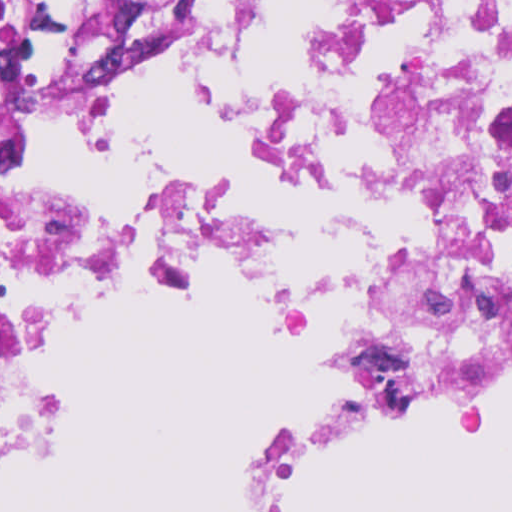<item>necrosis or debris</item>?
<instances>
[{"instance_id": "necrosis-or-debris-1", "label": "necrosis or debris", "mask_w": 512, "mask_h": 512, "mask_svg": "<svg viewBox=\"0 0 512 512\" xmlns=\"http://www.w3.org/2000/svg\"><path fill=\"white\" fill-rule=\"evenodd\" d=\"M465 2L468 44L381 99L371 143L410 217L405 251L340 310L238 209L108 214L11 175L66 111L124 91L95 59L0 89V459L18 442L41 351L23 320L44 274L126 257L271 292L353 357L270 449L240 497L283 498L305 468L512 375V0H335L317 74H364L410 22Z\"/></svg>"}]
</instances>
